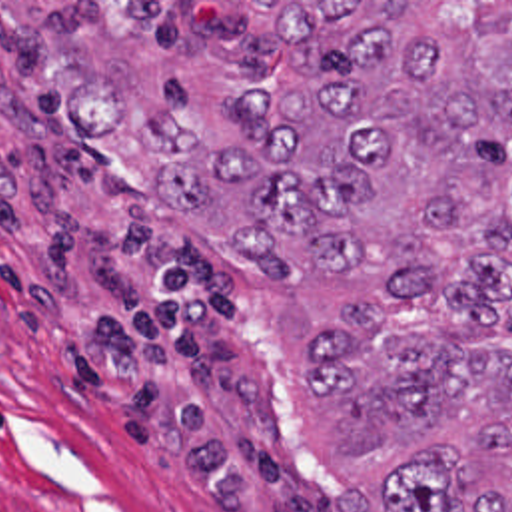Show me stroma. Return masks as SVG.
I'll list each match as a JSON object with an SVG mask.
<instances>
[{
    "instance_id": "stroma-1",
    "label": "stroma",
    "mask_w": 512,
    "mask_h": 512,
    "mask_svg": "<svg viewBox=\"0 0 512 512\" xmlns=\"http://www.w3.org/2000/svg\"><path fill=\"white\" fill-rule=\"evenodd\" d=\"M269 2L512 0H0V512L317 511L257 275L55 108L125 82L211 138L285 54Z\"/></svg>"
}]
</instances>
